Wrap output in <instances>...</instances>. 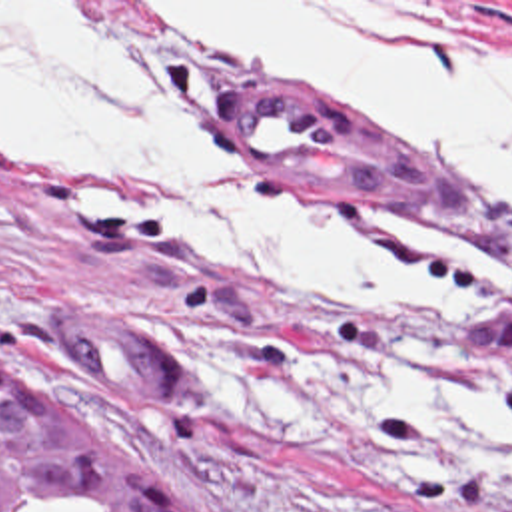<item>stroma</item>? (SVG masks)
<instances>
[{
  "label": "stroma",
  "instance_id": "1",
  "mask_svg": "<svg viewBox=\"0 0 512 512\" xmlns=\"http://www.w3.org/2000/svg\"><path fill=\"white\" fill-rule=\"evenodd\" d=\"M0 2L81 8L85 2L141 32L191 72L215 156L281 202L351 226L422 230L512 274V204L506 200L494 198L498 220H480L363 182L241 160L225 110L231 84L293 82L197 40L157 6L349 4L458 18L512 36V0ZM319 98L381 136L349 108ZM81 190H99L123 210H171L175 200L169 180L157 172L0 140L1 373L31 377L93 421L127 433L161 479L201 511L512 512V483L490 467L470 465L442 481L391 477L385 449L413 441L343 417L329 397L369 379L474 371L512 399V299L496 301L466 323H389L347 297L247 284L177 228L127 222L101 206L67 200ZM71 297L107 307L183 361L189 369L183 407H153L73 385L47 337L53 313Z\"/></svg>",
  "mask_w": 512,
  "mask_h": 512
}]
</instances>
